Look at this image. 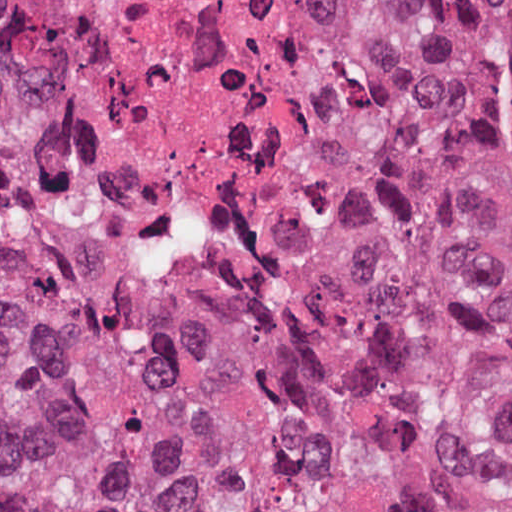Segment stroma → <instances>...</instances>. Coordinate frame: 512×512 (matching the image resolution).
Instances as JSON below:
<instances>
[{
  "mask_svg": "<svg viewBox=\"0 0 512 512\" xmlns=\"http://www.w3.org/2000/svg\"><path fill=\"white\" fill-rule=\"evenodd\" d=\"M346 24H347L346 15L344 14V21H343V26H342L341 31L346 26ZM335 82H336V41H335L334 45L332 46V77H331L329 91L327 94V100H326V106H325V111H324L319 146L322 141L325 123H326L327 116H328L330 106L332 103ZM112 217L127 232H129L131 234V236L135 239V241L139 244V246L143 249V251L145 253H147L148 255L153 257L156 261H158L159 263H161L162 265L167 267L166 264L164 263V261L162 260V258L160 257V255L155 250V247L148 241V239L143 234L133 231L122 221L115 218L114 216H112ZM320 218H321V215H320L317 194L311 188H309L305 217H304V224L310 232L314 228V226L317 224V222L320 220ZM304 316H306L308 319L313 320V321L332 324V323L326 322L324 320H321L319 318H316L314 316H310V315H304ZM332 325H334V324H332ZM334 326H337L339 328H342L344 330H347V331L357 335L358 337L364 339L365 341H367L368 343H370L371 345H373L377 348L411 352V353H414V354H417V355H420V356H423V357H426V358H429L432 360H484V361L512 364V358H510V357L503 356V355H497V354L489 353V352L482 351V350H462V349L447 348V347H441V346H437V345L430 344V343L408 341V340H402V339H397V338L368 334V333L355 331L350 328L338 326V325H334Z\"/></svg>",
  "mask_w": 512,
  "mask_h": 512,
  "instance_id": "1",
  "label": "stroma"
}]
</instances>
